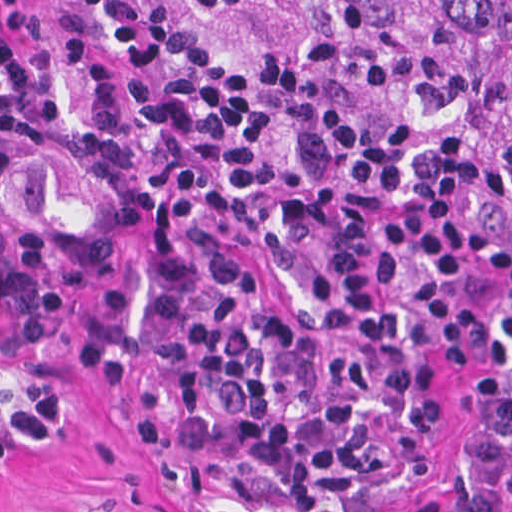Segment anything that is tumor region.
<instances>
[{
    "instance_id": "e687c5a6",
    "label": "tumor region",
    "mask_w": 512,
    "mask_h": 512,
    "mask_svg": "<svg viewBox=\"0 0 512 512\" xmlns=\"http://www.w3.org/2000/svg\"><path fill=\"white\" fill-rule=\"evenodd\" d=\"M302 19H342L417 65L444 71L471 120L512 143V0H249Z\"/></svg>"
}]
</instances>
